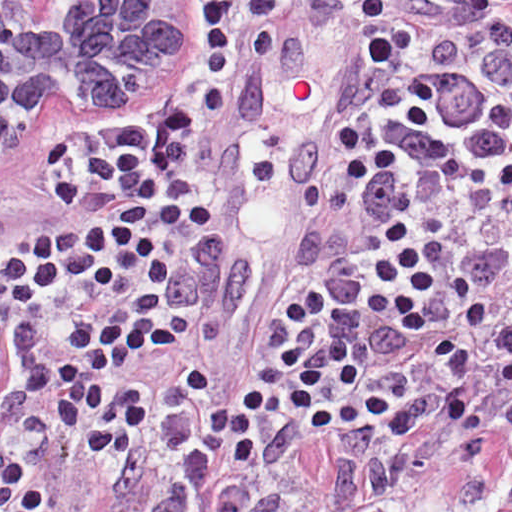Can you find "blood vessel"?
I'll return each instance as SVG.
<instances>
[{"label":"blood vessel","instance_id":"8fb6f2fc","mask_svg":"<svg viewBox=\"0 0 512 512\" xmlns=\"http://www.w3.org/2000/svg\"><path fill=\"white\" fill-rule=\"evenodd\" d=\"M364 106L337 39L291 18L253 45L185 260L201 278L216 372L244 318L303 269Z\"/></svg>","mask_w":512,"mask_h":512}]
</instances>
